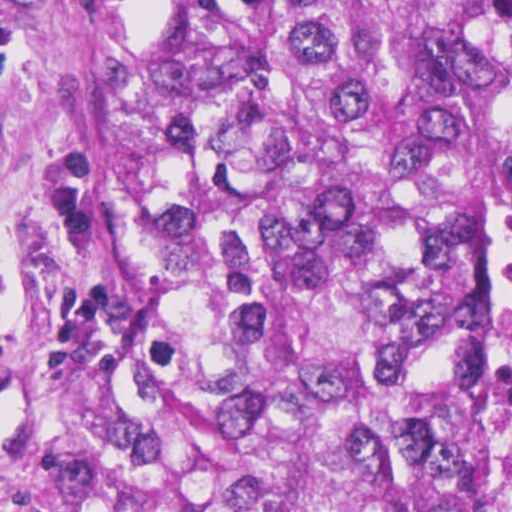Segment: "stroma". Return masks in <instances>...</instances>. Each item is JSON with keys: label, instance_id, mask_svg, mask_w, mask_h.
Masks as SVG:
<instances>
[{"label": "stroma", "instance_id": "1", "mask_svg": "<svg viewBox=\"0 0 512 512\" xmlns=\"http://www.w3.org/2000/svg\"><path fill=\"white\" fill-rule=\"evenodd\" d=\"M512 0H453V512H493L490 75ZM145 239V0H0V512L115 444Z\"/></svg>", "mask_w": 512, "mask_h": 512}]
</instances>
